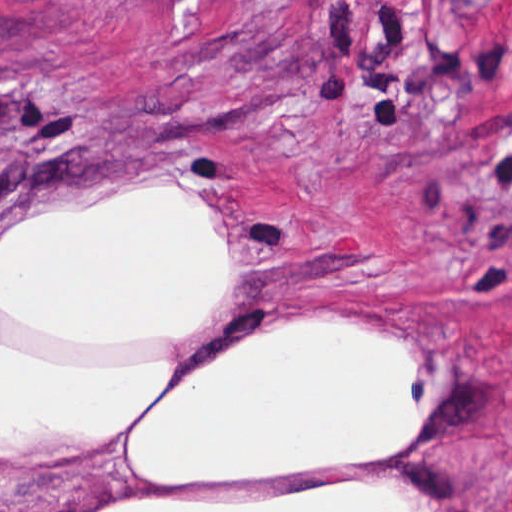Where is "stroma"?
Listing matches in <instances>:
<instances>
[{
	"label": "stroma",
	"mask_w": 512,
	"mask_h": 512,
	"mask_svg": "<svg viewBox=\"0 0 512 512\" xmlns=\"http://www.w3.org/2000/svg\"><path fill=\"white\" fill-rule=\"evenodd\" d=\"M164 181L236 231L174 379L334 318L419 341L434 420L392 461L286 483L144 482L114 437L0 460V512L373 480L512 512V0H0V244Z\"/></svg>",
	"instance_id": "obj_1"
}]
</instances>
